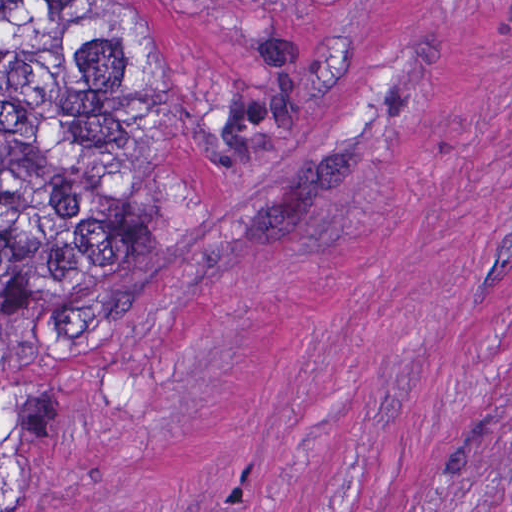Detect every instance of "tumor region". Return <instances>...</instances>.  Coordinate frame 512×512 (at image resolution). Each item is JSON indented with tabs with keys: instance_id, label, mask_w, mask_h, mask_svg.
Instances as JSON below:
<instances>
[{
	"instance_id": "e687c5a6",
	"label": "tumor region",
	"mask_w": 512,
	"mask_h": 512,
	"mask_svg": "<svg viewBox=\"0 0 512 512\" xmlns=\"http://www.w3.org/2000/svg\"><path fill=\"white\" fill-rule=\"evenodd\" d=\"M149 112L140 10L0 1V512H34L37 364L142 258Z\"/></svg>"
}]
</instances>
